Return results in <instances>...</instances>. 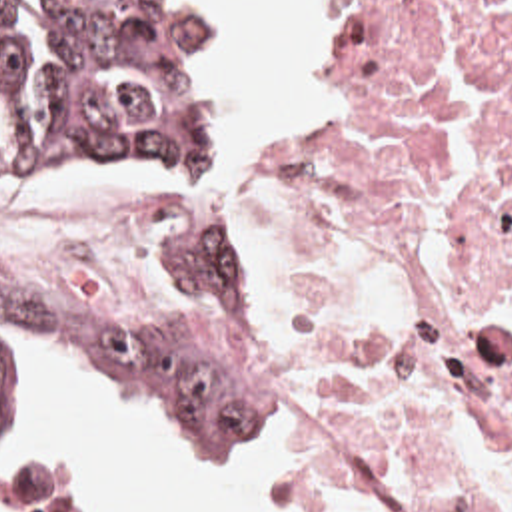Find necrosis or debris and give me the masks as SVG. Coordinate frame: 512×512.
Masks as SVG:
<instances>
[{"instance_id":"necrosis-or-debris-1","label":"necrosis or debris","mask_w":512,"mask_h":512,"mask_svg":"<svg viewBox=\"0 0 512 512\" xmlns=\"http://www.w3.org/2000/svg\"><path fill=\"white\" fill-rule=\"evenodd\" d=\"M0 201V271L124 299L190 199ZM262 374L312 422L298 512H512V0H372L332 153L274 195Z\"/></svg>"}]
</instances>
